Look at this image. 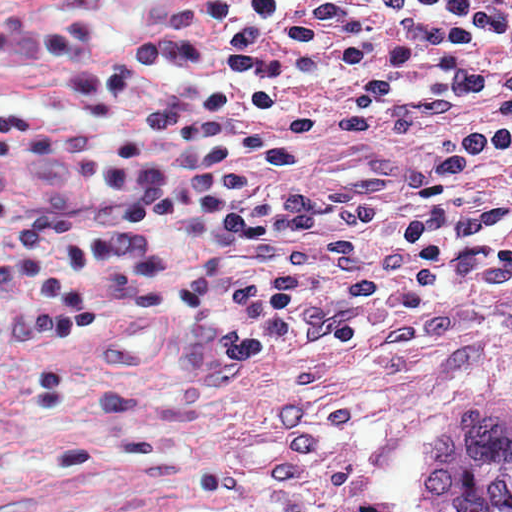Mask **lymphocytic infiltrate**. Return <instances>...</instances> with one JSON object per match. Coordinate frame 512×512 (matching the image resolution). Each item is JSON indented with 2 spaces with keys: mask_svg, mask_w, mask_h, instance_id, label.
Returning a JSON list of instances; mask_svg holds the SVG:
<instances>
[{
  "mask_svg": "<svg viewBox=\"0 0 512 512\" xmlns=\"http://www.w3.org/2000/svg\"><path fill=\"white\" fill-rule=\"evenodd\" d=\"M208 15L227 89L88 147L124 232L224 229L189 280L192 379H225L286 333L339 343L440 280L512 264V103L461 144L277 193L313 132L299 92L354 74L349 109L379 122L512 79V0H211Z\"/></svg>",
  "mask_w": 512,
  "mask_h": 512,
  "instance_id": "f902f5d3",
  "label": "lymphocytic infiltrate"
}]
</instances>
